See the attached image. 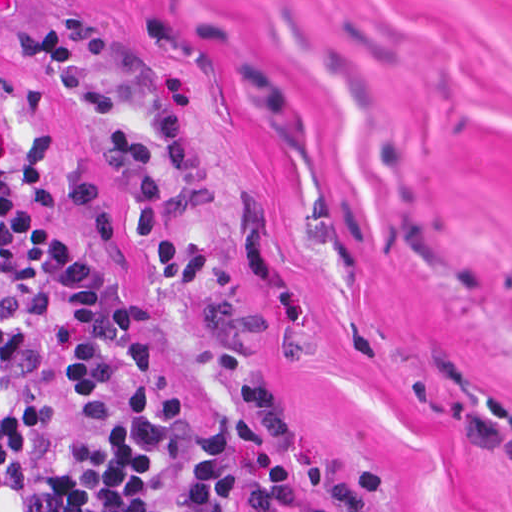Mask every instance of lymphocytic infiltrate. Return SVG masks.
<instances>
[{
	"label": "lymphocytic infiltrate",
	"mask_w": 512,
	"mask_h": 512,
	"mask_svg": "<svg viewBox=\"0 0 512 512\" xmlns=\"http://www.w3.org/2000/svg\"><path fill=\"white\" fill-rule=\"evenodd\" d=\"M0 512H267L224 380L51 228L1 127Z\"/></svg>",
	"instance_id": "obj_1"
}]
</instances>
